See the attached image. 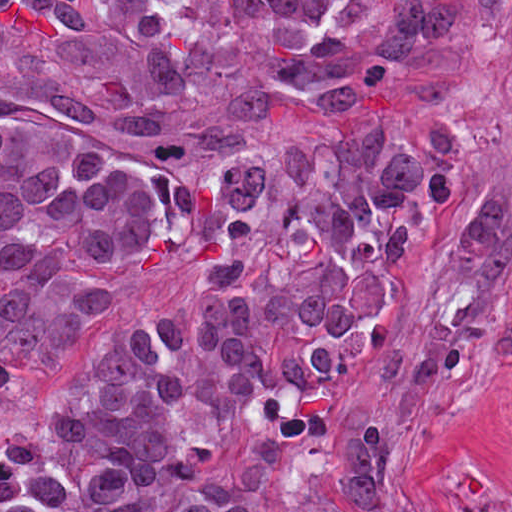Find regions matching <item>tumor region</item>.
Masks as SVG:
<instances>
[{"mask_svg": "<svg viewBox=\"0 0 512 512\" xmlns=\"http://www.w3.org/2000/svg\"><path fill=\"white\" fill-rule=\"evenodd\" d=\"M486 185L466 108L0 315V512H444L363 352L463 219L376 370L421 390L512 335ZM450 512H512V484Z\"/></svg>", "mask_w": 512, "mask_h": 512, "instance_id": "obj_1", "label": "tumor region"}]
</instances>
